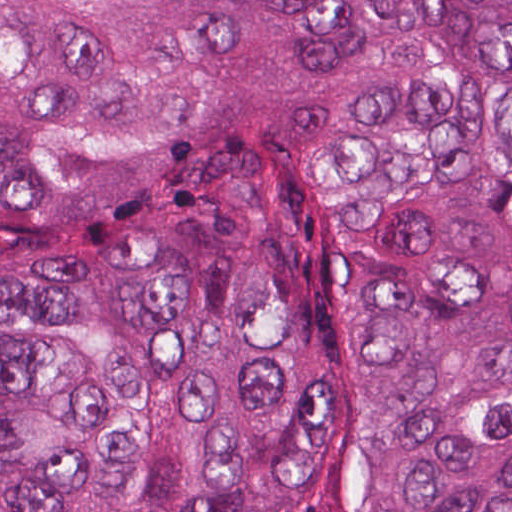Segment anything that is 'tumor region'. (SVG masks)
Listing matches in <instances>:
<instances>
[{"label": "tumor region", "instance_id": "e687c5a6", "mask_svg": "<svg viewBox=\"0 0 512 512\" xmlns=\"http://www.w3.org/2000/svg\"><path fill=\"white\" fill-rule=\"evenodd\" d=\"M0 512H512V0H1Z\"/></svg>", "mask_w": 512, "mask_h": 512}]
</instances>
